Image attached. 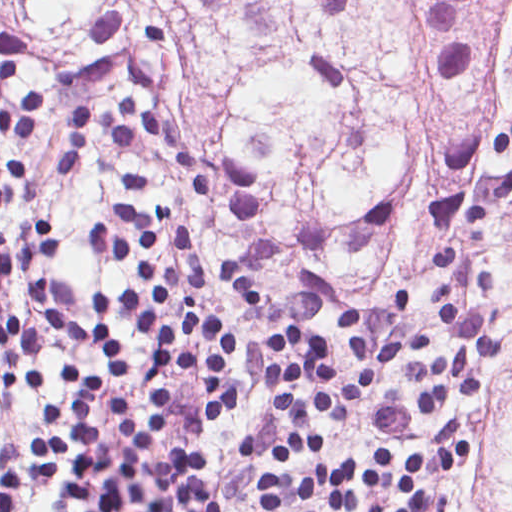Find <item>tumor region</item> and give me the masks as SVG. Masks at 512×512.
I'll return each mask as SVG.
<instances>
[{
  "label": "tumor region",
  "instance_id": "e687c5a6",
  "mask_svg": "<svg viewBox=\"0 0 512 512\" xmlns=\"http://www.w3.org/2000/svg\"><path fill=\"white\" fill-rule=\"evenodd\" d=\"M62 84L185 83L234 164L231 282L411 285L422 231L512 219V0H0ZM512 338V296L498 299ZM484 464L448 512H512V351Z\"/></svg>",
  "mask_w": 512,
  "mask_h": 512
}]
</instances>
